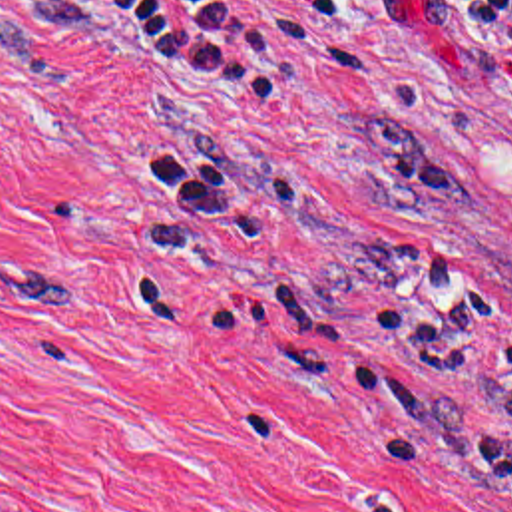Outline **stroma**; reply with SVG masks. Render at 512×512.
I'll return each mask as SVG.
<instances>
[{"instance_id": "1", "label": "stroma", "mask_w": 512, "mask_h": 512, "mask_svg": "<svg viewBox=\"0 0 512 512\" xmlns=\"http://www.w3.org/2000/svg\"><path fill=\"white\" fill-rule=\"evenodd\" d=\"M464 258L503 326L422 369L356 252ZM266 284L338 344L185 316ZM512 91L444 0H0V512H512L474 481L512 391ZM448 391L410 415L324 387Z\"/></svg>"}]
</instances>
